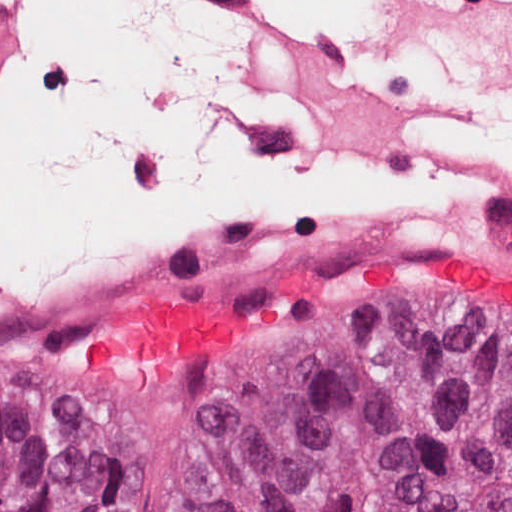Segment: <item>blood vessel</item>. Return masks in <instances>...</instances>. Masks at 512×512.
<instances>
[{
    "label": "blood vessel",
    "mask_w": 512,
    "mask_h": 512,
    "mask_svg": "<svg viewBox=\"0 0 512 512\" xmlns=\"http://www.w3.org/2000/svg\"><path fill=\"white\" fill-rule=\"evenodd\" d=\"M22 25L13 8L0 5L3 69L19 41ZM349 250H512V204L379 225H297L213 248L124 255L74 270L26 302L0 310V322L79 308L212 265Z\"/></svg>",
    "instance_id": "1"
}]
</instances>
